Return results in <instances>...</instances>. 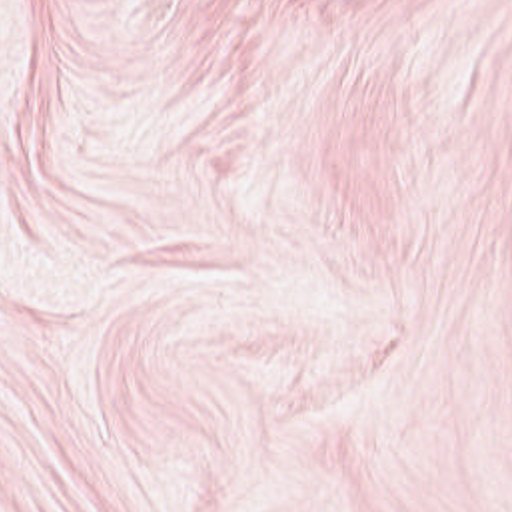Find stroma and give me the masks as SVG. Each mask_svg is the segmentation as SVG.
<instances>
[{
	"instance_id": "35a3bbf8",
	"label": "stroma",
	"mask_w": 512,
	"mask_h": 512,
	"mask_svg": "<svg viewBox=\"0 0 512 512\" xmlns=\"http://www.w3.org/2000/svg\"><path fill=\"white\" fill-rule=\"evenodd\" d=\"M0 512H512V0H0Z\"/></svg>"
}]
</instances>
